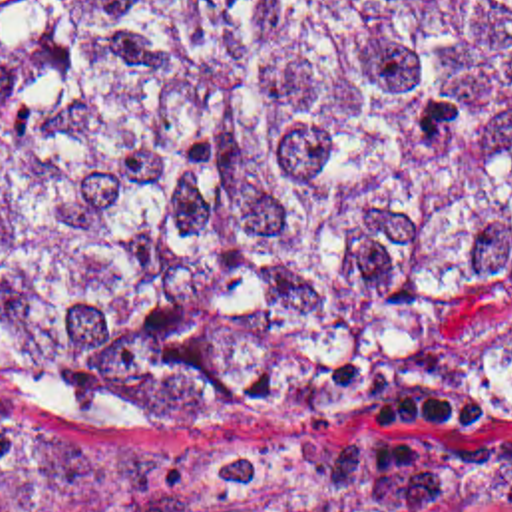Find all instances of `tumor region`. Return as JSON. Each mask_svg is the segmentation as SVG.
Masks as SVG:
<instances>
[{"instance_id":"1","label":"tumor region","mask_w":512,"mask_h":512,"mask_svg":"<svg viewBox=\"0 0 512 512\" xmlns=\"http://www.w3.org/2000/svg\"><path fill=\"white\" fill-rule=\"evenodd\" d=\"M512 282V0H0V373L115 431L386 451ZM512 501V465L0 419V512Z\"/></svg>"}]
</instances>
